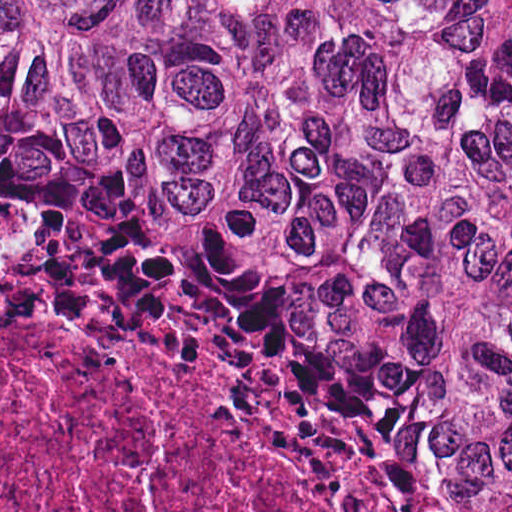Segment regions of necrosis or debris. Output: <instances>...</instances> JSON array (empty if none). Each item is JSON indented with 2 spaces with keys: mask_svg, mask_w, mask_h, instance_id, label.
<instances>
[{
  "mask_svg": "<svg viewBox=\"0 0 512 512\" xmlns=\"http://www.w3.org/2000/svg\"><path fill=\"white\" fill-rule=\"evenodd\" d=\"M0 512H359L269 462L195 371L0 281Z\"/></svg>",
  "mask_w": 512,
  "mask_h": 512,
  "instance_id": "4bbe7bcc",
  "label": "necrosis or debris"
}]
</instances>
